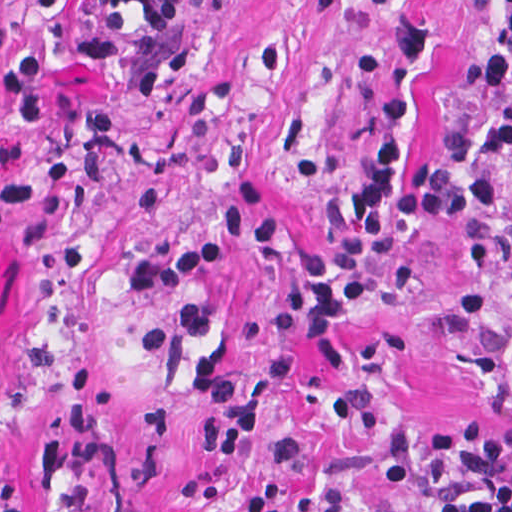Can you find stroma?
<instances>
[{"label": "stroma", "instance_id": "stroma-1", "mask_svg": "<svg viewBox=\"0 0 512 512\" xmlns=\"http://www.w3.org/2000/svg\"><path fill=\"white\" fill-rule=\"evenodd\" d=\"M92 0H0V70ZM432 54L407 167L482 119L505 0H413ZM392 16L178 0L98 64L54 56L38 122L0 98V512H418L436 435L512 420V163L501 248L435 223L387 251L326 373L300 258L341 224Z\"/></svg>", "mask_w": 512, "mask_h": 512}]
</instances>
